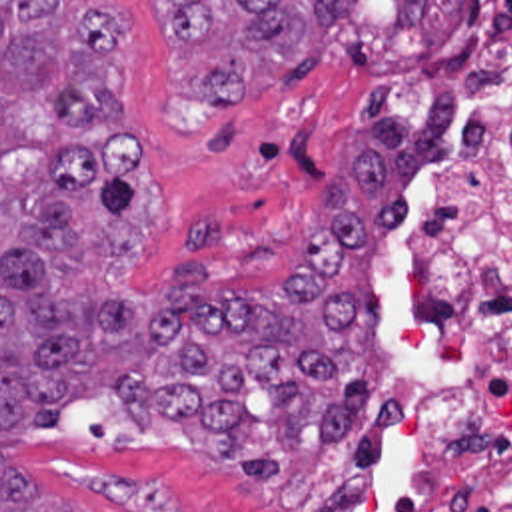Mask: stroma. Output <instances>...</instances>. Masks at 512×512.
<instances>
[{"instance_id":"35a3bbf8","label":"stroma","mask_w":512,"mask_h":512,"mask_svg":"<svg viewBox=\"0 0 512 512\" xmlns=\"http://www.w3.org/2000/svg\"><path fill=\"white\" fill-rule=\"evenodd\" d=\"M130 20L122 82L130 122L150 148L166 188V220L144 270L150 292L166 268L196 260L214 292L282 282L290 248L316 230L310 212L322 184L350 166L362 136L358 104L388 78L398 110L418 124L461 44L463 18L436 56L420 28L398 26L394 0H362L348 36L324 52L296 54L280 82L244 106H214L192 74L250 38L246 16H226L212 40L178 50L154 0H110ZM380 312L368 389L390 362L394 340V230L374 254ZM258 425L244 451L276 455L280 475H246L222 459L214 429L186 419L150 427L114 395L68 403L64 423L22 437L6 457L32 485L86 512L286 511L290 483L324 437L286 445L274 427L276 395H246Z\"/></svg>"}]
</instances>
